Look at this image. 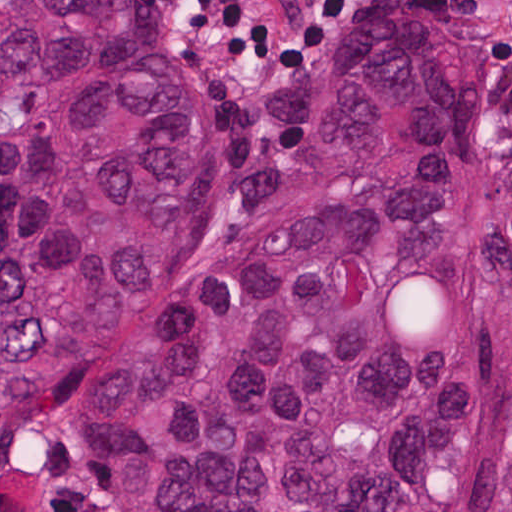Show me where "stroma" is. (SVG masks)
<instances>
[{"instance_id": "obj_1", "label": "stroma", "mask_w": 512, "mask_h": 512, "mask_svg": "<svg viewBox=\"0 0 512 512\" xmlns=\"http://www.w3.org/2000/svg\"><path fill=\"white\" fill-rule=\"evenodd\" d=\"M339 1L151 0L214 133V185L195 249L242 232L283 171L289 139L269 149L253 131L251 84L260 77L269 84L317 79L346 16L382 8H432L453 22L472 70L479 209L507 208L500 170L512 162V0H361L336 14L326 34L286 69H259L201 45H296L324 25ZM0 512H114L84 453L65 387L1 427V0Z\"/></svg>"}]
</instances>
